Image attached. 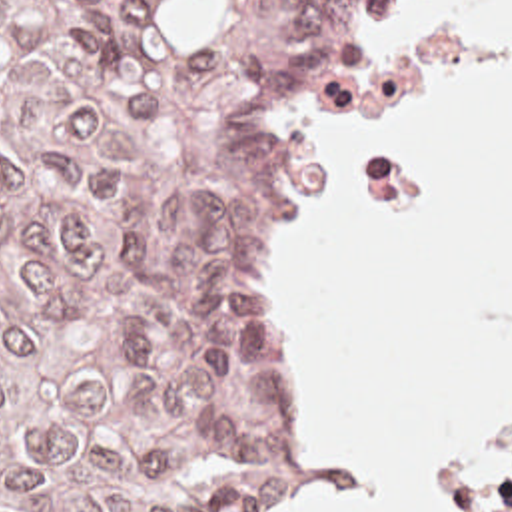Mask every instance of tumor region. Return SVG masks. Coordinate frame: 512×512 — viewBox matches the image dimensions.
Wrapping results in <instances>:
<instances>
[{
	"label": "tumor region",
	"instance_id": "tumor-region-1",
	"mask_svg": "<svg viewBox=\"0 0 512 512\" xmlns=\"http://www.w3.org/2000/svg\"><path fill=\"white\" fill-rule=\"evenodd\" d=\"M366 1L0 0V512L286 482L282 153Z\"/></svg>",
	"mask_w": 512,
	"mask_h": 512
}]
</instances>
